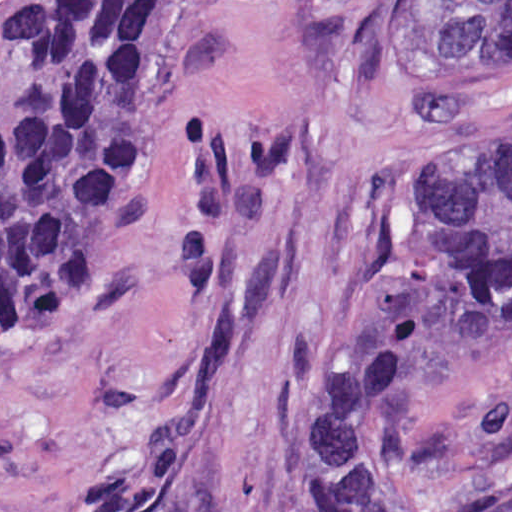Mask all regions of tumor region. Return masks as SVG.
I'll return each instance as SVG.
<instances>
[{
    "instance_id": "obj_1",
    "label": "tumor region",
    "mask_w": 512,
    "mask_h": 512,
    "mask_svg": "<svg viewBox=\"0 0 512 512\" xmlns=\"http://www.w3.org/2000/svg\"><path fill=\"white\" fill-rule=\"evenodd\" d=\"M178 0H15L0 25V316L33 336L96 325L141 111ZM394 41L426 72L512 57V0H400ZM207 56L223 64L207 41ZM512 336V135L434 175L388 311L312 401L311 512H441L411 453L427 400Z\"/></svg>"
}]
</instances>
